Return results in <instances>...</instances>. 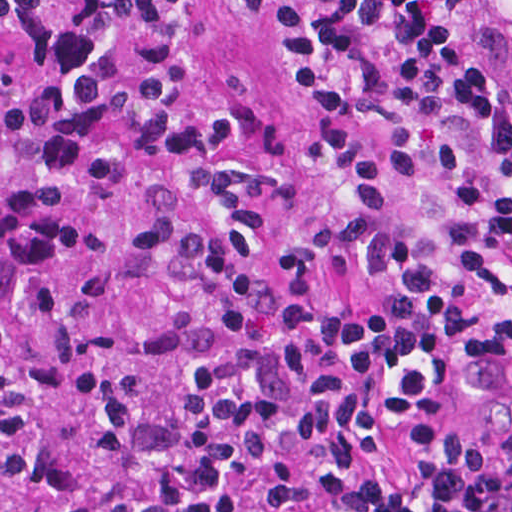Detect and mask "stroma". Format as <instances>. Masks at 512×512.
I'll return each instance as SVG.
<instances>
[{
  "mask_svg": "<svg viewBox=\"0 0 512 512\" xmlns=\"http://www.w3.org/2000/svg\"><path fill=\"white\" fill-rule=\"evenodd\" d=\"M0 69L26 90H129L146 69L142 39H119L68 67L40 59L38 42L0 20ZM223 104L239 108L230 147H252L269 124L281 126L283 157L296 199L267 212L258 234L267 248L316 253L332 301L376 304L382 293L371 271L348 252L338 221L354 213L347 179L321 167L319 143L327 128L358 140L378 160L387 144L370 128L330 110L299 105L273 90L272 36L263 16L224 0H188L184 16L183 73L167 104L168 117L208 115ZM347 353V347H346ZM512 425V360L492 381L476 365L457 379L450 401L436 413L394 422L375 453V468L398 480L413 464V441L430 430H452L468 439L492 437Z\"/></svg>",
  "mask_w": 512,
  "mask_h": 512,
  "instance_id": "1",
  "label": "stroma"
}]
</instances>
